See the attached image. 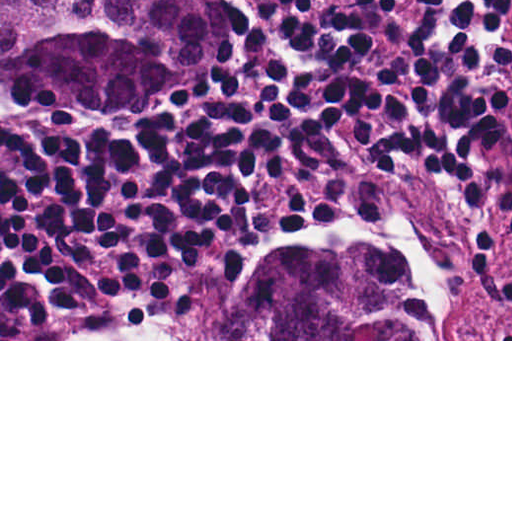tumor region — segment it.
I'll return each mask as SVG.
<instances>
[{
  "label": "tumor region",
  "mask_w": 512,
  "mask_h": 512,
  "mask_svg": "<svg viewBox=\"0 0 512 512\" xmlns=\"http://www.w3.org/2000/svg\"><path fill=\"white\" fill-rule=\"evenodd\" d=\"M218 72L195 0H1V81L39 110L168 96ZM174 339H442L388 249L308 247L275 261L245 302L209 288Z\"/></svg>",
  "instance_id": "e687c5a6"
}]
</instances>
